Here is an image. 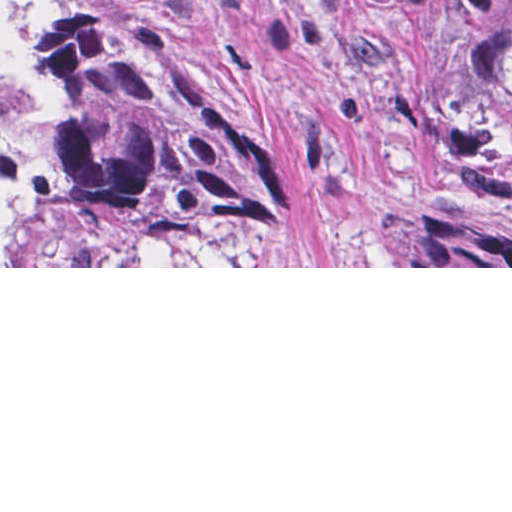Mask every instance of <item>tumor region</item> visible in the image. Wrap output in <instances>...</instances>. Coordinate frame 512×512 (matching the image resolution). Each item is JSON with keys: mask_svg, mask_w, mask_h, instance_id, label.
<instances>
[{"mask_svg": "<svg viewBox=\"0 0 512 512\" xmlns=\"http://www.w3.org/2000/svg\"><path fill=\"white\" fill-rule=\"evenodd\" d=\"M416 115L464 125L512 198V0H311ZM274 152L130 0H0V266L138 212H252ZM486 223V222H485ZM398 209L392 266H512V237Z\"/></svg>", "mask_w": 512, "mask_h": 512, "instance_id": "obj_1", "label": "tumor region"}]
</instances>
